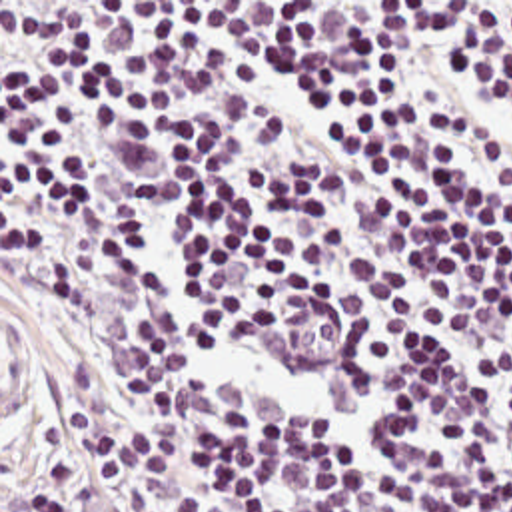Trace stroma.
Wrapping results in <instances>:
<instances>
[{"label":"stroma","instance_id":"stroma-1","mask_svg":"<svg viewBox=\"0 0 512 512\" xmlns=\"http://www.w3.org/2000/svg\"><path fill=\"white\" fill-rule=\"evenodd\" d=\"M18 413L68 357L78 321L64 293L0 246Z\"/></svg>","mask_w":512,"mask_h":512}]
</instances>
